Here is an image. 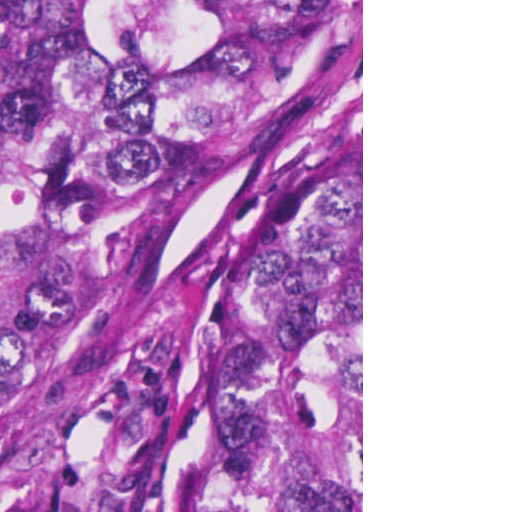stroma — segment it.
<instances>
[{"label":"stroma","mask_w":512,"mask_h":512,"mask_svg":"<svg viewBox=\"0 0 512 512\" xmlns=\"http://www.w3.org/2000/svg\"><path fill=\"white\" fill-rule=\"evenodd\" d=\"M361 149L363 0H326L214 171L52 225L0 317V512H185L202 380L241 282Z\"/></svg>","instance_id":"obj_1"}]
</instances>
